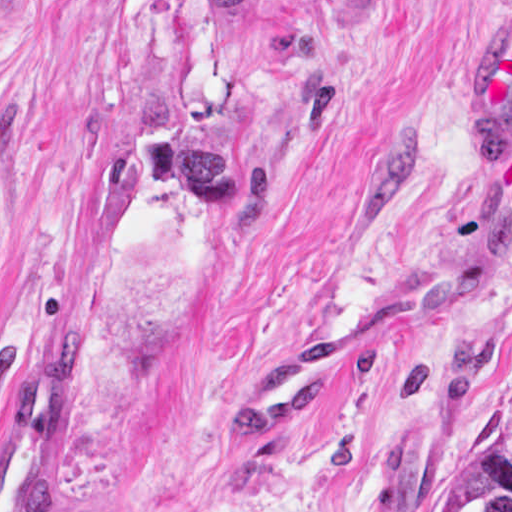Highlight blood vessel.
Segmentation results:
<instances>
[{"mask_svg":"<svg viewBox=\"0 0 512 512\" xmlns=\"http://www.w3.org/2000/svg\"><path fill=\"white\" fill-rule=\"evenodd\" d=\"M469 128L495 149L512 144V0L473 85ZM427 317L428 294L420 290L324 319L239 384L225 409L231 438L261 442L337 398L400 334ZM86 421L87 370L69 338L0 436V512H45Z\"/></svg>","mask_w":512,"mask_h":512,"instance_id":"obj_1","label":"blood vessel"}]
</instances>
